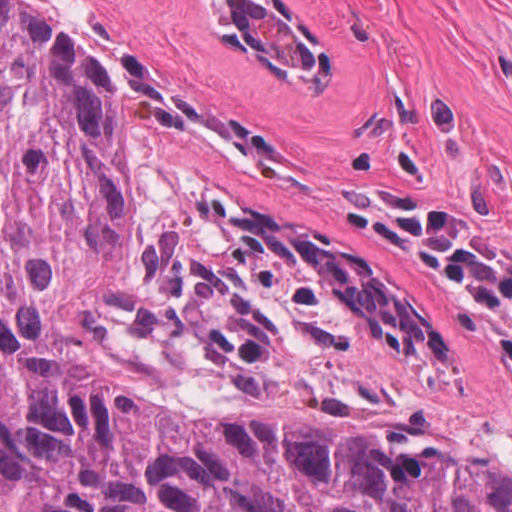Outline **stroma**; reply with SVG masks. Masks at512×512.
<instances>
[{"label":"stroma","mask_w":512,"mask_h":512,"mask_svg":"<svg viewBox=\"0 0 512 512\" xmlns=\"http://www.w3.org/2000/svg\"><path fill=\"white\" fill-rule=\"evenodd\" d=\"M105 73L147 157L322 246L425 316L448 373L311 366L512 475L507 367L446 284L348 200L401 193L512 251V0H16ZM224 190H222V189Z\"/></svg>","instance_id":"1"}]
</instances>
